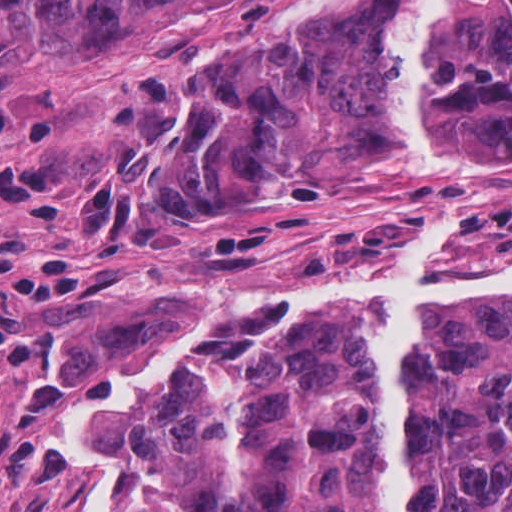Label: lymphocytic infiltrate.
<instances>
[{
    "mask_svg": "<svg viewBox=\"0 0 512 512\" xmlns=\"http://www.w3.org/2000/svg\"><path fill=\"white\" fill-rule=\"evenodd\" d=\"M51 118L27 103H0V215L55 220L73 203L58 162L24 146L50 144ZM108 267L96 244H49L0 222V385L44 378L66 312L87 298Z\"/></svg>",
    "mask_w": 512,
    "mask_h": 512,
    "instance_id": "obj_1",
    "label": "lymphocytic infiltrate"
}]
</instances>
